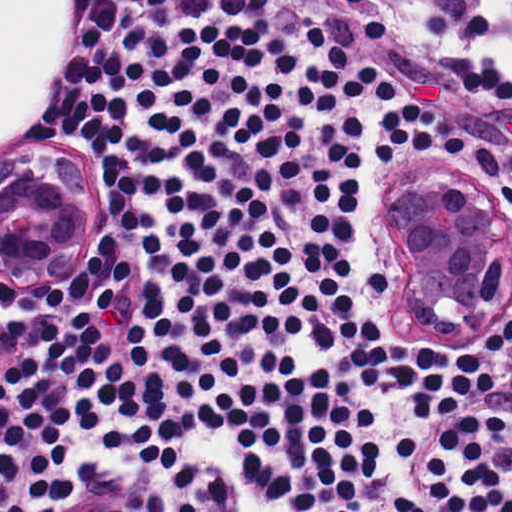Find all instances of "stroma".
<instances>
[{
	"instance_id": "obj_1",
	"label": "stroma",
	"mask_w": 512,
	"mask_h": 512,
	"mask_svg": "<svg viewBox=\"0 0 512 512\" xmlns=\"http://www.w3.org/2000/svg\"><path fill=\"white\" fill-rule=\"evenodd\" d=\"M273 2L285 21L326 23L361 68L374 66L395 82L397 98L383 100L374 93L376 145L383 116L391 108L422 100L440 106L460 129L480 139L512 143V104L464 87L468 72L483 64L512 76L510 0ZM25 140L33 146H50L57 141L44 132L43 118L28 131ZM1 147L7 146H1L0 0V275ZM101 475H108V470H101Z\"/></svg>"
}]
</instances>
